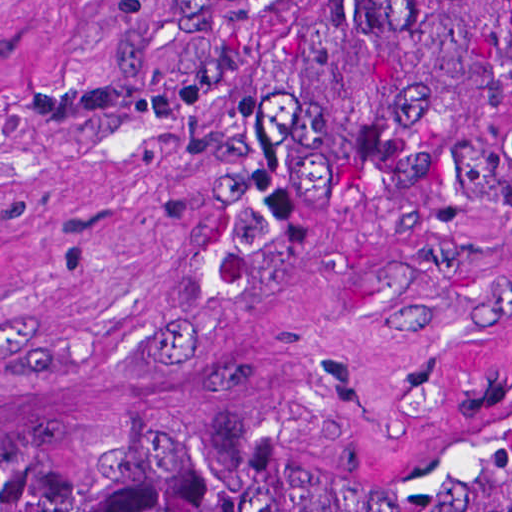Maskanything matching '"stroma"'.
Returning <instances> with one entry per match:
<instances>
[{"label":"stroma","mask_w":512,"mask_h":512,"mask_svg":"<svg viewBox=\"0 0 512 512\" xmlns=\"http://www.w3.org/2000/svg\"><path fill=\"white\" fill-rule=\"evenodd\" d=\"M512 61V0H489ZM145 0H0V434H279L402 480L512 415V107L341 224L285 372L237 366V203L137 82ZM279 51L360 0H269Z\"/></svg>","instance_id":"stroma-1"}]
</instances>
